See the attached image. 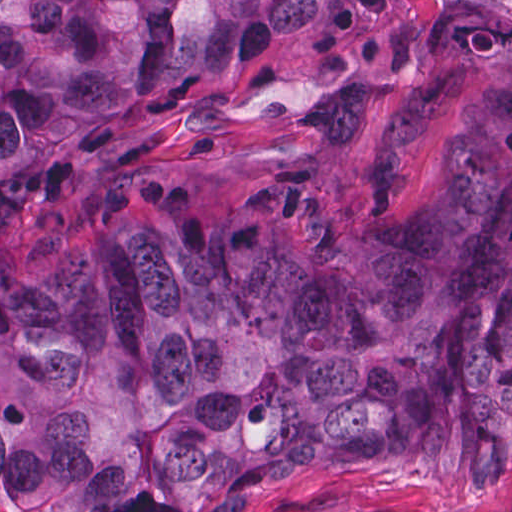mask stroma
Segmentation results:
<instances>
[{"label":"stroma","mask_w":512,"mask_h":512,"mask_svg":"<svg viewBox=\"0 0 512 512\" xmlns=\"http://www.w3.org/2000/svg\"><path fill=\"white\" fill-rule=\"evenodd\" d=\"M512 0H359L337 33L266 50L213 84L178 124L138 128L100 166L22 198H1V268L36 260L121 202H139L184 237H209L272 202L341 230L410 211L453 167L459 110L428 107L380 186L387 125L408 75L466 8ZM235 512H512V477L459 497L379 476L290 475Z\"/></svg>","instance_id":"1"}]
</instances>
